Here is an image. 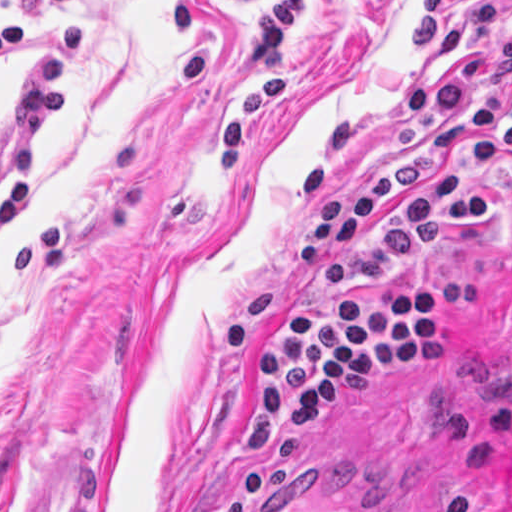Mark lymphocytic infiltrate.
Wrapping results in <instances>:
<instances>
[{"label":"lymphocytic infiltrate","instance_id":"lymphocytic-infiltrate-1","mask_svg":"<svg viewBox=\"0 0 512 512\" xmlns=\"http://www.w3.org/2000/svg\"><path fill=\"white\" fill-rule=\"evenodd\" d=\"M0 0V61L21 42L20 23ZM44 0V33L0 117V231L25 209L38 166L41 132L69 105L68 81L85 40V19ZM305 0H256L249 7L251 61L258 64L219 130L221 175L237 167L264 106L287 92L282 32ZM512 0L472 1L448 21V0H421L403 37L407 56L436 51L457 69L444 80L414 83L399 104V153L380 174L338 189L356 148L351 118H340L302 168L300 185L323 197L309 205L293 251V291L254 292L247 313L222 340L233 352L243 328L271 305H301L256 358L259 381L237 434L241 460L276 436L310 425L419 359L446 339V294L416 285L383 294H349L402 270L447 230L495 223L504 206L496 178L512 177V26L498 30Z\"/></svg>","mask_w":512,"mask_h":512}]
</instances>
